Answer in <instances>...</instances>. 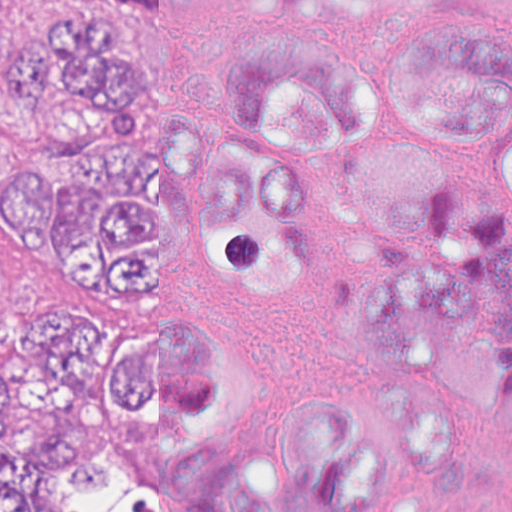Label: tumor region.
<instances>
[{
  "label": "tumor region",
  "mask_w": 512,
  "mask_h": 512,
  "mask_svg": "<svg viewBox=\"0 0 512 512\" xmlns=\"http://www.w3.org/2000/svg\"><path fill=\"white\" fill-rule=\"evenodd\" d=\"M184 0L58 6L33 53L0 0V70L43 149L0 160V250L69 301L144 302V63L120 21L176 22ZM120 18V19H119ZM373 88L397 143L345 114V205L371 230L338 291L341 336L388 395L426 344H462L512 468V28L432 16L384 41ZM144 425V321L68 305L0 327V512H157Z\"/></svg>",
  "instance_id": "obj_1"
}]
</instances>
